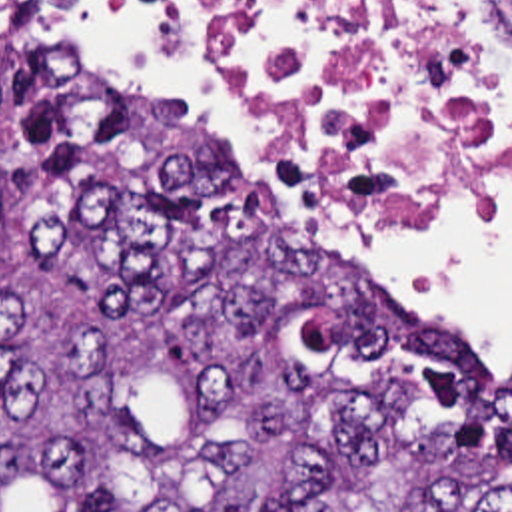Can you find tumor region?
I'll return each mask as SVG.
<instances>
[{
    "mask_svg": "<svg viewBox=\"0 0 512 512\" xmlns=\"http://www.w3.org/2000/svg\"><path fill=\"white\" fill-rule=\"evenodd\" d=\"M0 0V512H512V372Z\"/></svg>",
    "mask_w": 512,
    "mask_h": 512,
    "instance_id": "e687c5a6",
    "label": "tumor region"
}]
</instances>
